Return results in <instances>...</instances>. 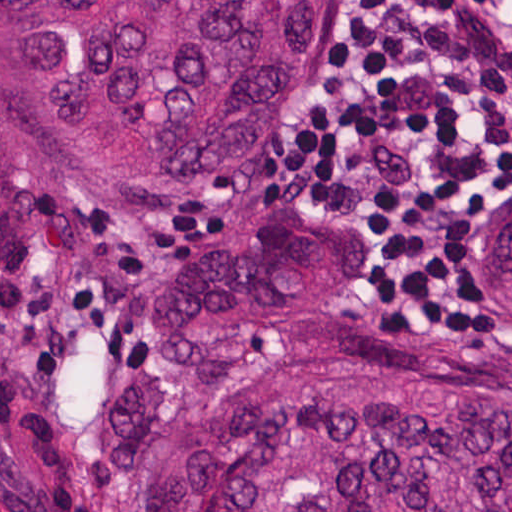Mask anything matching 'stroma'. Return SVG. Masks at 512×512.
Returning <instances> with one entry per match:
<instances>
[{"instance_id":"35a3bbf8","label":"stroma","mask_w":512,"mask_h":512,"mask_svg":"<svg viewBox=\"0 0 512 512\" xmlns=\"http://www.w3.org/2000/svg\"><path fill=\"white\" fill-rule=\"evenodd\" d=\"M366 0H340L309 72L284 98L246 169L175 210L108 218L54 192L48 220L0 269V512H151L139 498L113 431L112 375L129 364L178 357L150 324V290L195 223L243 207H317L340 229L365 308L382 317L500 311L464 285L473 223L512 208V175L456 199L444 279L427 293L383 286L360 252L342 206L303 204L279 192L262 155L307 121L319 73L355 31Z\"/></svg>"}]
</instances>
